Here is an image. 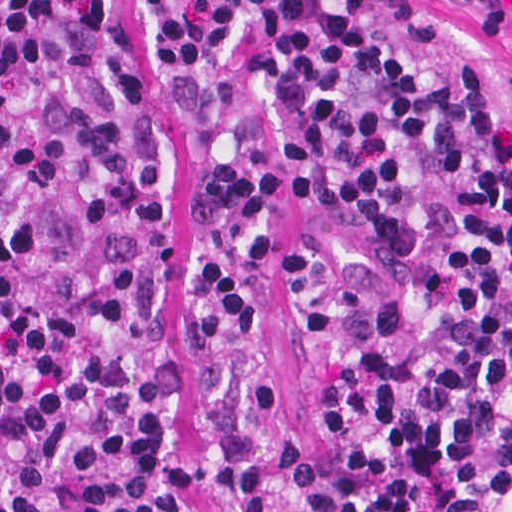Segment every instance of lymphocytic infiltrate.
Instances as JSON below:
<instances>
[{
    "label": "lymphocytic infiltrate",
    "instance_id": "f902f5d3",
    "mask_svg": "<svg viewBox=\"0 0 512 512\" xmlns=\"http://www.w3.org/2000/svg\"><path fill=\"white\" fill-rule=\"evenodd\" d=\"M178 114L229 94L244 43L265 148L196 179L194 223L267 253L285 190L349 221L354 265L282 269L311 367V449L211 483L223 512H512V126L430 0H138ZM125 0H0V512H188L196 422H248L273 382L183 360L246 336L218 260L196 326L157 305L168 144Z\"/></svg>",
    "mask_w": 512,
    "mask_h": 512
}]
</instances>
